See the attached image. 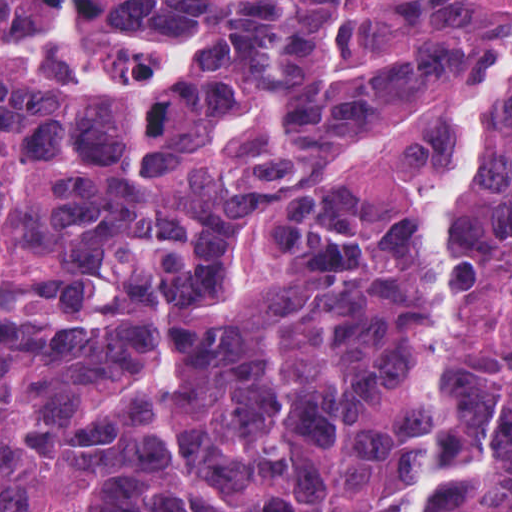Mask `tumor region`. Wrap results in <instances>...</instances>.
<instances>
[{
  "label": "tumor region",
  "instance_id": "1",
  "mask_svg": "<svg viewBox=\"0 0 512 512\" xmlns=\"http://www.w3.org/2000/svg\"><path fill=\"white\" fill-rule=\"evenodd\" d=\"M508 0H0V512H401L424 163ZM443 512H512V77L465 225Z\"/></svg>",
  "mask_w": 512,
  "mask_h": 512
}]
</instances>
